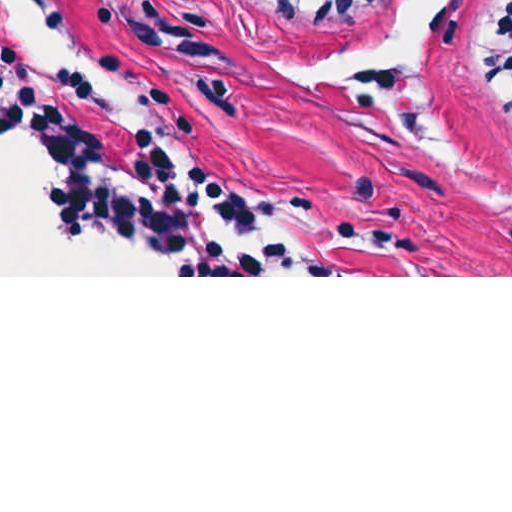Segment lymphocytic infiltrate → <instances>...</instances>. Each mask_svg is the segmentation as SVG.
Here are the masks:
<instances>
[{
    "label": "lymphocytic infiltrate",
    "mask_w": 512,
    "mask_h": 512,
    "mask_svg": "<svg viewBox=\"0 0 512 512\" xmlns=\"http://www.w3.org/2000/svg\"><path fill=\"white\" fill-rule=\"evenodd\" d=\"M293 25H342L382 0H253ZM480 82L499 93L512 122V0L491 22ZM90 95L89 79L70 71L50 76L37 94L21 61L1 52V132L34 131L52 157L46 201L55 227L80 235L110 228L163 247L190 275H337L274 236L259 233V210L237 200L209 171L180 173L163 131L145 125L133 149L115 164L91 125L74 111Z\"/></svg>",
    "instance_id": "obj_1"
}]
</instances>
